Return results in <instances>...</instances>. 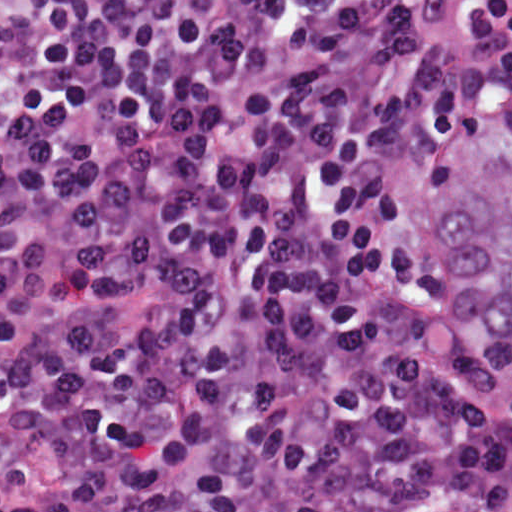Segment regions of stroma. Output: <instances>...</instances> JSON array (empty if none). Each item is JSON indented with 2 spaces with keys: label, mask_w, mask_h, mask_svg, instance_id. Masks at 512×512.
<instances>
[{
  "label": "stroma",
  "mask_w": 512,
  "mask_h": 512,
  "mask_svg": "<svg viewBox=\"0 0 512 512\" xmlns=\"http://www.w3.org/2000/svg\"><path fill=\"white\" fill-rule=\"evenodd\" d=\"M439 298L448 332L461 348L480 361L489 385L512 401V388L482 348L440 273ZM0 484L9 494L0 512H15L50 488L49 463L19 428L0 427Z\"/></svg>",
  "instance_id": "obj_1"
}]
</instances>
